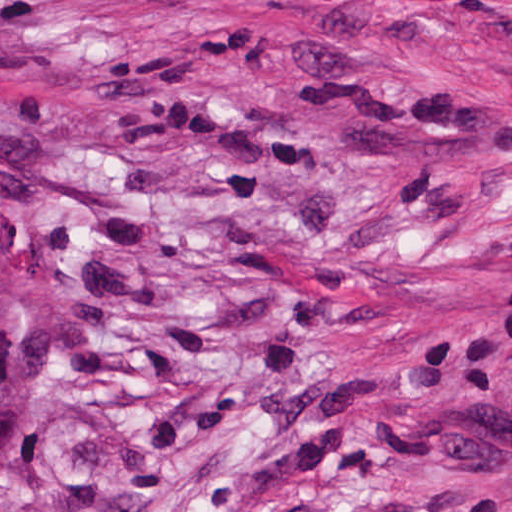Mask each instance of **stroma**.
<instances>
[{"mask_svg":"<svg viewBox=\"0 0 512 512\" xmlns=\"http://www.w3.org/2000/svg\"><path fill=\"white\" fill-rule=\"evenodd\" d=\"M0 169V512H512V0H0Z\"/></svg>","mask_w":512,"mask_h":512,"instance_id":"1","label":"stroma"}]
</instances>
